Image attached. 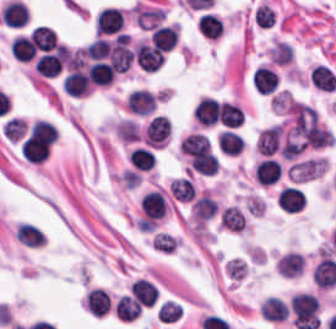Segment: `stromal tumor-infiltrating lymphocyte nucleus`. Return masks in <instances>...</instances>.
<instances>
[{
	"instance_id": "13",
	"label": "stromal tumor-infiltrating lymphocyte nucleus",
	"mask_w": 336,
	"mask_h": 329,
	"mask_svg": "<svg viewBox=\"0 0 336 329\" xmlns=\"http://www.w3.org/2000/svg\"><path fill=\"white\" fill-rule=\"evenodd\" d=\"M178 37L176 25H157L150 33V43L170 51L174 48Z\"/></svg>"
},
{
	"instance_id": "19",
	"label": "stromal tumor-infiltrating lymphocyte nucleus",
	"mask_w": 336,
	"mask_h": 329,
	"mask_svg": "<svg viewBox=\"0 0 336 329\" xmlns=\"http://www.w3.org/2000/svg\"><path fill=\"white\" fill-rule=\"evenodd\" d=\"M170 191L179 202H191L196 197V186L187 176L171 180Z\"/></svg>"
},
{
	"instance_id": "11",
	"label": "stromal tumor-infiltrating lymphocyte nucleus",
	"mask_w": 336,
	"mask_h": 329,
	"mask_svg": "<svg viewBox=\"0 0 336 329\" xmlns=\"http://www.w3.org/2000/svg\"><path fill=\"white\" fill-rule=\"evenodd\" d=\"M281 172L282 167L279 160L265 158L260 160L256 168V181L263 186H271L277 183Z\"/></svg>"
},
{
	"instance_id": "27",
	"label": "stromal tumor-infiltrating lymphocyte nucleus",
	"mask_w": 336,
	"mask_h": 329,
	"mask_svg": "<svg viewBox=\"0 0 336 329\" xmlns=\"http://www.w3.org/2000/svg\"><path fill=\"white\" fill-rule=\"evenodd\" d=\"M116 315L121 320H134L142 310L139 304L128 295H121L116 306Z\"/></svg>"
},
{
	"instance_id": "3",
	"label": "stromal tumor-infiltrating lymphocyte nucleus",
	"mask_w": 336,
	"mask_h": 329,
	"mask_svg": "<svg viewBox=\"0 0 336 329\" xmlns=\"http://www.w3.org/2000/svg\"><path fill=\"white\" fill-rule=\"evenodd\" d=\"M136 56L138 65L146 72H156L164 61L163 51L143 40L136 47Z\"/></svg>"
},
{
	"instance_id": "8",
	"label": "stromal tumor-infiltrating lymphocyte nucleus",
	"mask_w": 336,
	"mask_h": 329,
	"mask_svg": "<svg viewBox=\"0 0 336 329\" xmlns=\"http://www.w3.org/2000/svg\"><path fill=\"white\" fill-rule=\"evenodd\" d=\"M130 292L136 301L143 306H153L159 296L156 285L144 278H137L130 286Z\"/></svg>"
},
{
	"instance_id": "30",
	"label": "stromal tumor-infiltrating lymphocyte nucleus",
	"mask_w": 336,
	"mask_h": 329,
	"mask_svg": "<svg viewBox=\"0 0 336 329\" xmlns=\"http://www.w3.org/2000/svg\"><path fill=\"white\" fill-rule=\"evenodd\" d=\"M182 315V306L171 301L164 300L159 304L157 317L162 322H174Z\"/></svg>"
},
{
	"instance_id": "9",
	"label": "stromal tumor-infiltrating lymphocyte nucleus",
	"mask_w": 336,
	"mask_h": 329,
	"mask_svg": "<svg viewBox=\"0 0 336 329\" xmlns=\"http://www.w3.org/2000/svg\"><path fill=\"white\" fill-rule=\"evenodd\" d=\"M305 259L300 252L288 251L279 257L277 271L283 277H296L303 273Z\"/></svg>"
},
{
	"instance_id": "32",
	"label": "stromal tumor-infiltrating lymphocyte nucleus",
	"mask_w": 336,
	"mask_h": 329,
	"mask_svg": "<svg viewBox=\"0 0 336 329\" xmlns=\"http://www.w3.org/2000/svg\"><path fill=\"white\" fill-rule=\"evenodd\" d=\"M25 121L19 116H12L3 123L4 137L10 140H18L24 133Z\"/></svg>"
},
{
	"instance_id": "22",
	"label": "stromal tumor-infiltrating lymphocyte nucleus",
	"mask_w": 336,
	"mask_h": 329,
	"mask_svg": "<svg viewBox=\"0 0 336 329\" xmlns=\"http://www.w3.org/2000/svg\"><path fill=\"white\" fill-rule=\"evenodd\" d=\"M90 315L102 316L108 312L107 295L104 289L92 288L85 294Z\"/></svg>"
},
{
	"instance_id": "10",
	"label": "stromal tumor-infiltrating lymphocyte nucleus",
	"mask_w": 336,
	"mask_h": 329,
	"mask_svg": "<svg viewBox=\"0 0 336 329\" xmlns=\"http://www.w3.org/2000/svg\"><path fill=\"white\" fill-rule=\"evenodd\" d=\"M195 120L201 126H209L218 122L219 108L214 99L209 96H202L194 111Z\"/></svg>"
},
{
	"instance_id": "31",
	"label": "stromal tumor-infiltrating lymphocyte nucleus",
	"mask_w": 336,
	"mask_h": 329,
	"mask_svg": "<svg viewBox=\"0 0 336 329\" xmlns=\"http://www.w3.org/2000/svg\"><path fill=\"white\" fill-rule=\"evenodd\" d=\"M272 62L280 65H285L292 61L293 51L289 44L283 41H276L270 53Z\"/></svg>"
},
{
	"instance_id": "34",
	"label": "stromal tumor-infiltrating lymphocyte nucleus",
	"mask_w": 336,
	"mask_h": 329,
	"mask_svg": "<svg viewBox=\"0 0 336 329\" xmlns=\"http://www.w3.org/2000/svg\"><path fill=\"white\" fill-rule=\"evenodd\" d=\"M255 23L257 26L268 28L274 24V12L267 4H260L254 14Z\"/></svg>"
},
{
	"instance_id": "14",
	"label": "stromal tumor-infiltrating lymphocyte nucleus",
	"mask_w": 336,
	"mask_h": 329,
	"mask_svg": "<svg viewBox=\"0 0 336 329\" xmlns=\"http://www.w3.org/2000/svg\"><path fill=\"white\" fill-rule=\"evenodd\" d=\"M278 81V76L267 66L258 67L252 75V84L261 95L276 90Z\"/></svg>"
},
{
	"instance_id": "28",
	"label": "stromal tumor-infiltrating lymphocyte nucleus",
	"mask_w": 336,
	"mask_h": 329,
	"mask_svg": "<svg viewBox=\"0 0 336 329\" xmlns=\"http://www.w3.org/2000/svg\"><path fill=\"white\" fill-rule=\"evenodd\" d=\"M110 50V41L104 38H96L83 51L85 58L92 61H102Z\"/></svg>"
},
{
	"instance_id": "17",
	"label": "stromal tumor-infiltrating lymphocyte nucleus",
	"mask_w": 336,
	"mask_h": 329,
	"mask_svg": "<svg viewBox=\"0 0 336 329\" xmlns=\"http://www.w3.org/2000/svg\"><path fill=\"white\" fill-rule=\"evenodd\" d=\"M310 82L317 89L331 93L336 90L335 73L328 66L320 63L311 69Z\"/></svg>"
},
{
	"instance_id": "5",
	"label": "stromal tumor-infiltrating lymphocyte nucleus",
	"mask_w": 336,
	"mask_h": 329,
	"mask_svg": "<svg viewBox=\"0 0 336 329\" xmlns=\"http://www.w3.org/2000/svg\"><path fill=\"white\" fill-rule=\"evenodd\" d=\"M283 137V130L277 123L262 130L256 139V150L263 156L278 152Z\"/></svg>"
},
{
	"instance_id": "25",
	"label": "stromal tumor-infiltrating lymphocyte nucleus",
	"mask_w": 336,
	"mask_h": 329,
	"mask_svg": "<svg viewBox=\"0 0 336 329\" xmlns=\"http://www.w3.org/2000/svg\"><path fill=\"white\" fill-rule=\"evenodd\" d=\"M244 113L239 105L226 101H219V118L220 122L230 127L240 126Z\"/></svg>"
},
{
	"instance_id": "21",
	"label": "stromal tumor-infiltrating lymphocyte nucleus",
	"mask_w": 336,
	"mask_h": 329,
	"mask_svg": "<svg viewBox=\"0 0 336 329\" xmlns=\"http://www.w3.org/2000/svg\"><path fill=\"white\" fill-rule=\"evenodd\" d=\"M33 45L41 51H49L57 43L56 31L51 26L39 25L30 36Z\"/></svg>"
},
{
	"instance_id": "1",
	"label": "stromal tumor-infiltrating lymphocyte nucleus",
	"mask_w": 336,
	"mask_h": 329,
	"mask_svg": "<svg viewBox=\"0 0 336 329\" xmlns=\"http://www.w3.org/2000/svg\"><path fill=\"white\" fill-rule=\"evenodd\" d=\"M291 312L299 329H317L320 324L318 299L315 294L299 292L292 297Z\"/></svg>"
},
{
	"instance_id": "4",
	"label": "stromal tumor-infiltrating lymphocyte nucleus",
	"mask_w": 336,
	"mask_h": 329,
	"mask_svg": "<svg viewBox=\"0 0 336 329\" xmlns=\"http://www.w3.org/2000/svg\"><path fill=\"white\" fill-rule=\"evenodd\" d=\"M124 24L122 13L116 8L105 7L95 18V34H115Z\"/></svg>"
},
{
	"instance_id": "15",
	"label": "stromal tumor-infiltrating lymphocyte nucleus",
	"mask_w": 336,
	"mask_h": 329,
	"mask_svg": "<svg viewBox=\"0 0 336 329\" xmlns=\"http://www.w3.org/2000/svg\"><path fill=\"white\" fill-rule=\"evenodd\" d=\"M2 21L10 26H24L29 17V9L22 3L9 1L3 6L1 13Z\"/></svg>"
},
{
	"instance_id": "12",
	"label": "stromal tumor-infiltrating lymphocyte nucleus",
	"mask_w": 336,
	"mask_h": 329,
	"mask_svg": "<svg viewBox=\"0 0 336 329\" xmlns=\"http://www.w3.org/2000/svg\"><path fill=\"white\" fill-rule=\"evenodd\" d=\"M261 315L268 321H284L289 316V307L277 295H270L261 304Z\"/></svg>"
},
{
	"instance_id": "2",
	"label": "stromal tumor-infiltrating lymphocyte nucleus",
	"mask_w": 336,
	"mask_h": 329,
	"mask_svg": "<svg viewBox=\"0 0 336 329\" xmlns=\"http://www.w3.org/2000/svg\"><path fill=\"white\" fill-rule=\"evenodd\" d=\"M143 220L155 222L164 218L167 210V200L164 193L158 190L147 191L141 198Z\"/></svg>"
},
{
	"instance_id": "24",
	"label": "stromal tumor-infiltrating lymphocyte nucleus",
	"mask_w": 336,
	"mask_h": 329,
	"mask_svg": "<svg viewBox=\"0 0 336 329\" xmlns=\"http://www.w3.org/2000/svg\"><path fill=\"white\" fill-rule=\"evenodd\" d=\"M15 236L18 242L30 247H39L43 245L46 240L39 229L29 223H22L17 228Z\"/></svg>"
},
{
	"instance_id": "16",
	"label": "stromal tumor-infiltrating lymphocyte nucleus",
	"mask_w": 336,
	"mask_h": 329,
	"mask_svg": "<svg viewBox=\"0 0 336 329\" xmlns=\"http://www.w3.org/2000/svg\"><path fill=\"white\" fill-rule=\"evenodd\" d=\"M115 75L111 64L100 60L90 63L87 69V80L95 85L107 86L112 83Z\"/></svg>"
},
{
	"instance_id": "23",
	"label": "stromal tumor-infiltrating lymphocyte nucleus",
	"mask_w": 336,
	"mask_h": 329,
	"mask_svg": "<svg viewBox=\"0 0 336 329\" xmlns=\"http://www.w3.org/2000/svg\"><path fill=\"white\" fill-rule=\"evenodd\" d=\"M10 54L20 62H29L34 59L29 38L23 35H15L10 41Z\"/></svg>"
},
{
	"instance_id": "6",
	"label": "stromal tumor-infiltrating lymphocyte nucleus",
	"mask_w": 336,
	"mask_h": 329,
	"mask_svg": "<svg viewBox=\"0 0 336 329\" xmlns=\"http://www.w3.org/2000/svg\"><path fill=\"white\" fill-rule=\"evenodd\" d=\"M156 95L145 89H132L128 94L126 107L128 111L139 115H147L154 111Z\"/></svg>"
},
{
	"instance_id": "20",
	"label": "stromal tumor-infiltrating lymphocyte nucleus",
	"mask_w": 336,
	"mask_h": 329,
	"mask_svg": "<svg viewBox=\"0 0 336 329\" xmlns=\"http://www.w3.org/2000/svg\"><path fill=\"white\" fill-rule=\"evenodd\" d=\"M218 144L222 152L237 155L244 149L245 141L243 136L228 128L219 133Z\"/></svg>"
},
{
	"instance_id": "33",
	"label": "stromal tumor-infiltrating lymphocyte nucleus",
	"mask_w": 336,
	"mask_h": 329,
	"mask_svg": "<svg viewBox=\"0 0 336 329\" xmlns=\"http://www.w3.org/2000/svg\"><path fill=\"white\" fill-rule=\"evenodd\" d=\"M63 89L69 95L80 96L90 93L91 85L67 74L63 79Z\"/></svg>"
},
{
	"instance_id": "7",
	"label": "stromal tumor-infiltrating lymphocyte nucleus",
	"mask_w": 336,
	"mask_h": 329,
	"mask_svg": "<svg viewBox=\"0 0 336 329\" xmlns=\"http://www.w3.org/2000/svg\"><path fill=\"white\" fill-rule=\"evenodd\" d=\"M306 204V195L299 187L286 186L277 197V206L287 212H300Z\"/></svg>"
},
{
	"instance_id": "29",
	"label": "stromal tumor-infiltrating lymphocyte nucleus",
	"mask_w": 336,
	"mask_h": 329,
	"mask_svg": "<svg viewBox=\"0 0 336 329\" xmlns=\"http://www.w3.org/2000/svg\"><path fill=\"white\" fill-rule=\"evenodd\" d=\"M128 158L138 170H150L154 166V157L143 147L131 149Z\"/></svg>"
},
{
	"instance_id": "18",
	"label": "stromal tumor-infiltrating lymphocyte nucleus",
	"mask_w": 336,
	"mask_h": 329,
	"mask_svg": "<svg viewBox=\"0 0 336 329\" xmlns=\"http://www.w3.org/2000/svg\"><path fill=\"white\" fill-rule=\"evenodd\" d=\"M62 68L63 62L54 51L41 55L35 61V70L40 77L54 78Z\"/></svg>"
},
{
	"instance_id": "26",
	"label": "stromal tumor-infiltrating lymphocyte nucleus",
	"mask_w": 336,
	"mask_h": 329,
	"mask_svg": "<svg viewBox=\"0 0 336 329\" xmlns=\"http://www.w3.org/2000/svg\"><path fill=\"white\" fill-rule=\"evenodd\" d=\"M220 225L239 233L246 226V218L239 208L228 206L220 214Z\"/></svg>"
}]
</instances>
